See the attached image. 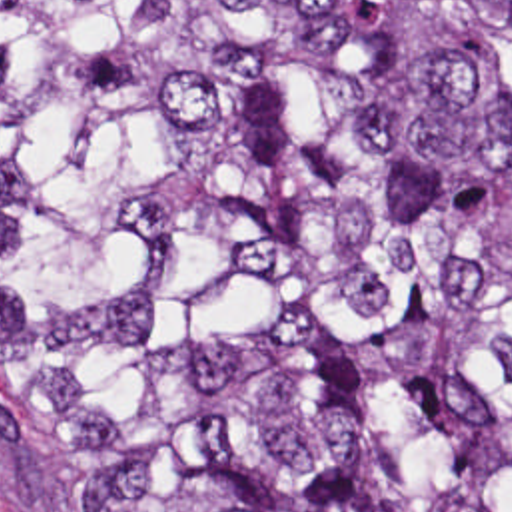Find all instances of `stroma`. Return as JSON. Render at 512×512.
<instances>
[{
    "label": "stroma",
    "instance_id": "1",
    "mask_svg": "<svg viewBox=\"0 0 512 512\" xmlns=\"http://www.w3.org/2000/svg\"><path fill=\"white\" fill-rule=\"evenodd\" d=\"M0 512H39L33 479L0 401Z\"/></svg>",
    "mask_w": 512,
    "mask_h": 512
}]
</instances>
